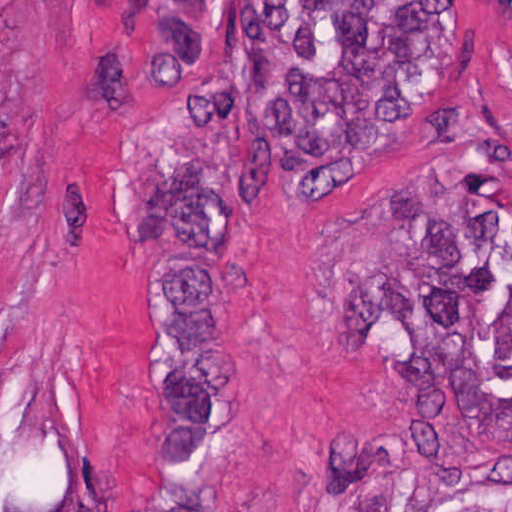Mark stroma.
Segmentation results:
<instances>
[{
  "label": "stroma",
  "mask_w": 512,
  "mask_h": 512,
  "mask_svg": "<svg viewBox=\"0 0 512 512\" xmlns=\"http://www.w3.org/2000/svg\"><path fill=\"white\" fill-rule=\"evenodd\" d=\"M465 1L454 62L376 154L233 211L227 512H512V0ZM143 2L0 0V455L78 512L162 499Z\"/></svg>",
  "instance_id": "35a3bbf8"
}]
</instances>
